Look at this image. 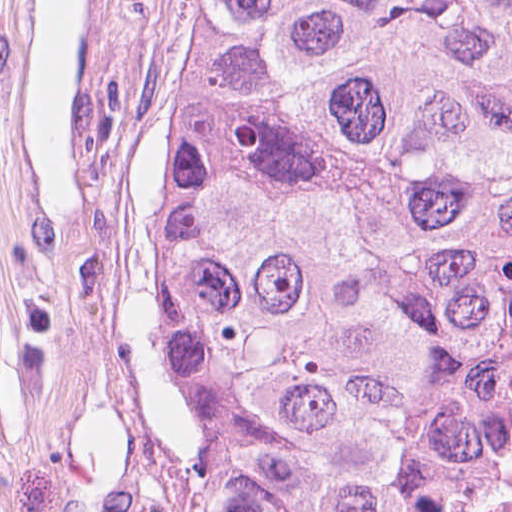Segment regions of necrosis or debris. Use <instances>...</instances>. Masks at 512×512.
Here are the masks:
<instances>
[{"label":"necrosis or debris","mask_w":512,"mask_h":512,"mask_svg":"<svg viewBox=\"0 0 512 512\" xmlns=\"http://www.w3.org/2000/svg\"><path fill=\"white\" fill-rule=\"evenodd\" d=\"M425 512H512V290L495 323Z\"/></svg>","instance_id":"obj_1"}]
</instances>
